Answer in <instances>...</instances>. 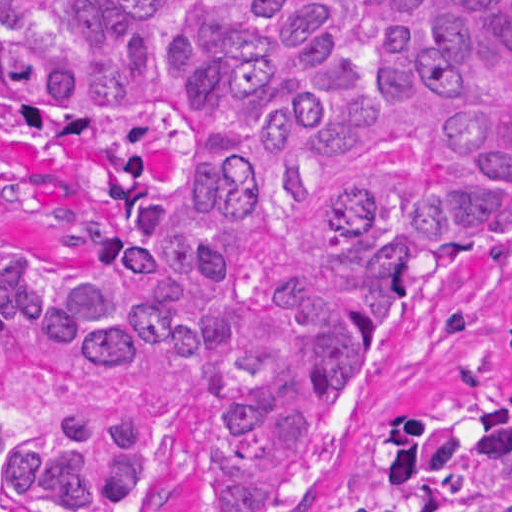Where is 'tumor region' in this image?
Returning <instances> with one entry per match:
<instances>
[{"label": "tumor region", "instance_id": "tumor-region-1", "mask_svg": "<svg viewBox=\"0 0 512 512\" xmlns=\"http://www.w3.org/2000/svg\"><path fill=\"white\" fill-rule=\"evenodd\" d=\"M166 113L80 245L1 240V512H129L182 417L285 512L395 307L512 238V0H1V118ZM385 512H512V391L405 419Z\"/></svg>", "mask_w": 512, "mask_h": 512}]
</instances>
